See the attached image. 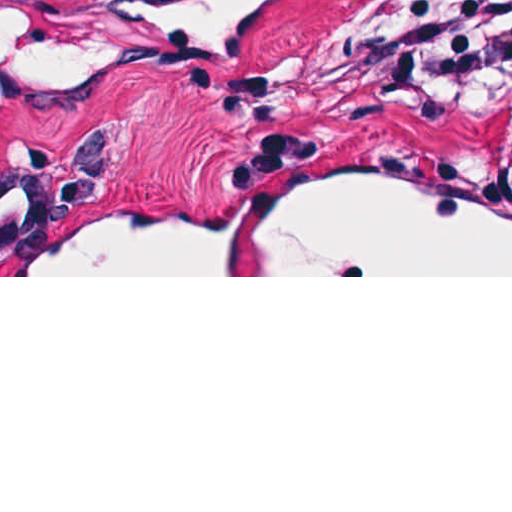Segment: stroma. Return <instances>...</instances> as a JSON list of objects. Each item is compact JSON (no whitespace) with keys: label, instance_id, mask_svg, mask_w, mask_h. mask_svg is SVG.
Returning <instances> with one entry per match:
<instances>
[{"label":"stroma","instance_id":"stroma-1","mask_svg":"<svg viewBox=\"0 0 512 512\" xmlns=\"http://www.w3.org/2000/svg\"><path fill=\"white\" fill-rule=\"evenodd\" d=\"M400 1L285 0L261 51L231 69L120 74L35 107L0 102V277H512L15 276L168 201H271L300 150H424L512 195L490 138L507 106L381 68L370 33Z\"/></svg>","mask_w":512,"mask_h":512}]
</instances>
